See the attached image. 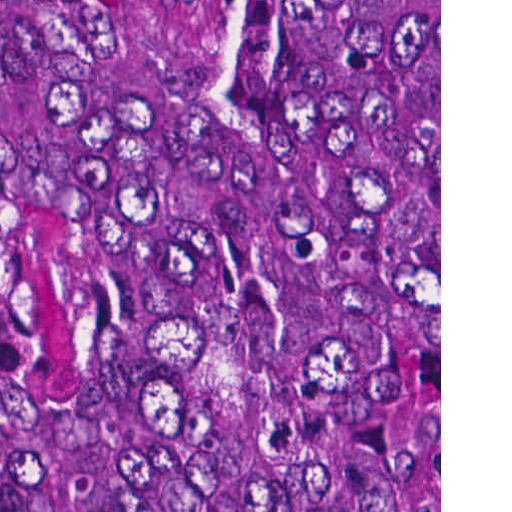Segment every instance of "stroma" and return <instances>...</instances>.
I'll return each mask as SVG.
<instances>
[{
    "instance_id": "obj_1",
    "label": "stroma",
    "mask_w": 512,
    "mask_h": 512,
    "mask_svg": "<svg viewBox=\"0 0 512 512\" xmlns=\"http://www.w3.org/2000/svg\"><path fill=\"white\" fill-rule=\"evenodd\" d=\"M142 136L126 197L274 185L342 220L270 78L250 17L218 0H136ZM439 512H441V0H439Z\"/></svg>"
}]
</instances>
